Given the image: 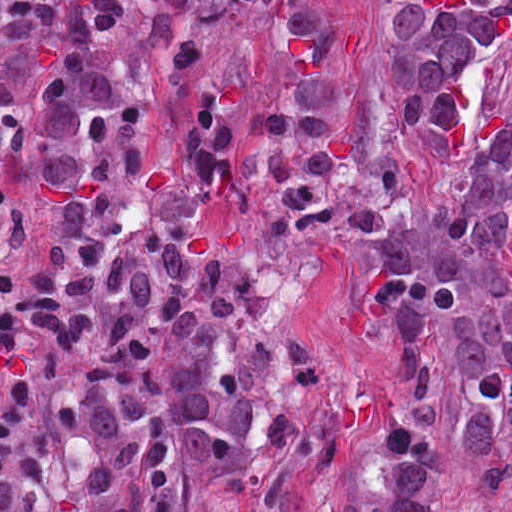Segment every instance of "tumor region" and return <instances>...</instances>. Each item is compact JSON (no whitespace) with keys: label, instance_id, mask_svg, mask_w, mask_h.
Segmentation results:
<instances>
[{"label":"tumor region","instance_id":"obj_1","mask_svg":"<svg viewBox=\"0 0 512 512\" xmlns=\"http://www.w3.org/2000/svg\"><path fill=\"white\" fill-rule=\"evenodd\" d=\"M363 1L0 0V421L239 316L246 265L300 234L405 223L351 128ZM511 29L512 0H382L404 129L458 130ZM511 155L506 130L452 220L509 195Z\"/></svg>","mask_w":512,"mask_h":512}]
</instances>
